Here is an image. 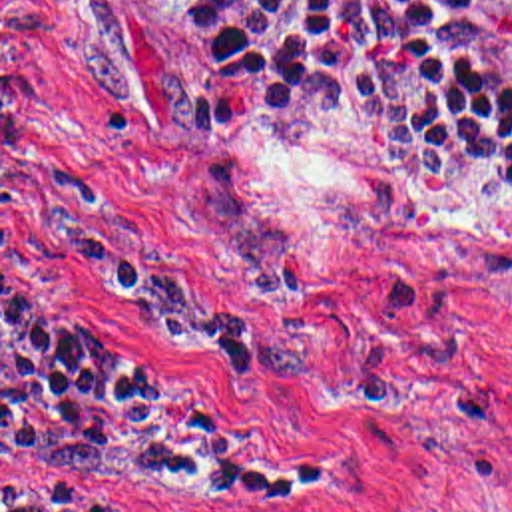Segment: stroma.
Returning <instances> with one entry per match:
<instances>
[{
	"label": "stroma",
	"mask_w": 512,
	"mask_h": 512,
	"mask_svg": "<svg viewBox=\"0 0 512 512\" xmlns=\"http://www.w3.org/2000/svg\"><path fill=\"white\" fill-rule=\"evenodd\" d=\"M2 298L197 384L275 480L2 474ZM92 512H512V171L372 105L239 103L173 0H0L2 492Z\"/></svg>",
	"instance_id": "35a3bbf8"
}]
</instances>
